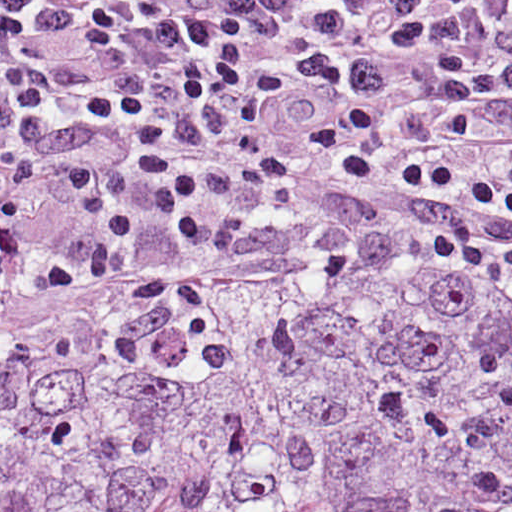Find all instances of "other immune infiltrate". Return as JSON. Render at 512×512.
Wrapping results in <instances>:
<instances>
[{
	"instance_id": "obj_1",
	"label": "other immune infiltrate",
	"mask_w": 512,
	"mask_h": 512,
	"mask_svg": "<svg viewBox=\"0 0 512 512\" xmlns=\"http://www.w3.org/2000/svg\"><path fill=\"white\" fill-rule=\"evenodd\" d=\"M348 242L293 256H272L133 216L66 219L0 252V314L36 307L74 291L318 259Z\"/></svg>"
}]
</instances>
